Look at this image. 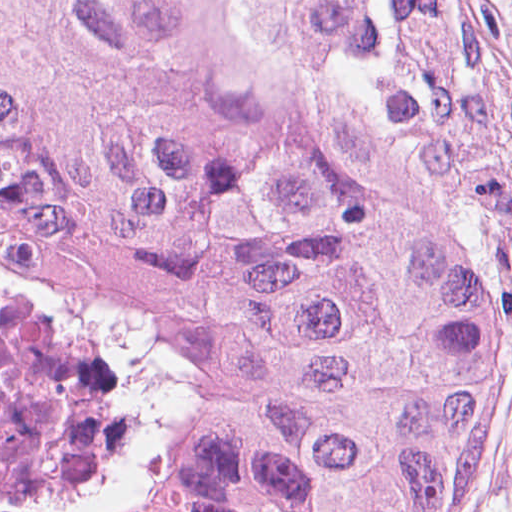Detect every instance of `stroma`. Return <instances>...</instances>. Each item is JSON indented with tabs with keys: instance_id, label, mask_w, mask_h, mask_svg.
Segmentation results:
<instances>
[{
	"instance_id": "stroma-1",
	"label": "stroma",
	"mask_w": 512,
	"mask_h": 512,
	"mask_svg": "<svg viewBox=\"0 0 512 512\" xmlns=\"http://www.w3.org/2000/svg\"><path fill=\"white\" fill-rule=\"evenodd\" d=\"M488 74L512 175V0H482ZM450 512H512V390L483 437Z\"/></svg>"
}]
</instances>
